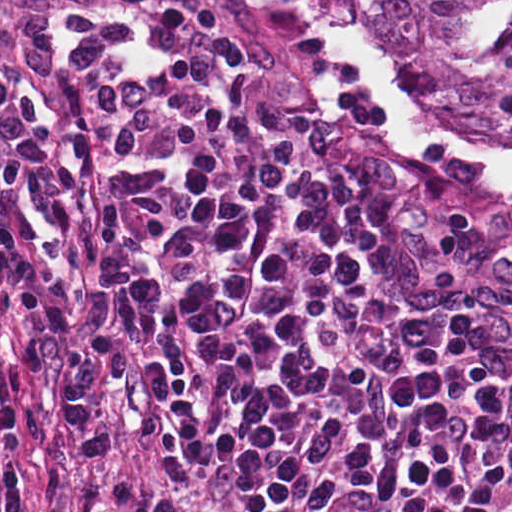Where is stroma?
I'll use <instances>...</instances> for the list:
<instances>
[{
	"mask_svg": "<svg viewBox=\"0 0 512 512\" xmlns=\"http://www.w3.org/2000/svg\"><path fill=\"white\" fill-rule=\"evenodd\" d=\"M204 2L225 26L237 112L254 146L293 185L324 187L343 199L388 281L440 291L496 322L512 389V176L389 123L358 73L330 59L295 0ZM322 3L343 45L369 67L332 1ZM374 75L428 115L512 148V79ZM20 334L18 318L5 316L17 434L0 452V512H41L47 500L68 512H124L147 494L194 512H225L138 431L133 383L93 352L85 332L107 448L93 459L80 454L63 350L48 342L45 375L28 378L17 358Z\"/></svg>",
	"mask_w": 512,
	"mask_h": 512,
	"instance_id": "obj_1",
	"label": "stroma"
}]
</instances>
